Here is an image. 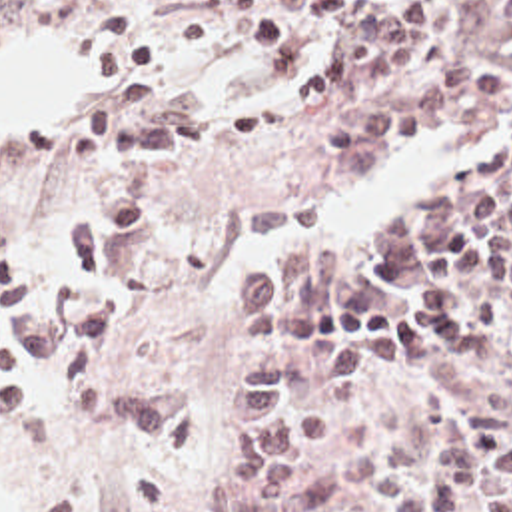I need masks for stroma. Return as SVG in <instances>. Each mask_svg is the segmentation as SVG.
Listing matches in <instances>:
<instances>
[{"instance_id":"1","label":"stroma","mask_w":512,"mask_h":512,"mask_svg":"<svg viewBox=\"0 0 512 512\" xmlns=\"http://www.w3.org/2000/svg\"><path fill=\"white\" fill-rule=\"evenodd\" d=\"M511 1L457 0L401 73L345 87L323 109H293L285 87L337 49L339 35L323 21L309 57L291 73L271 77L283 99L277 131L250 145L164 151L158 157V203L144 235L130 249L110 251L100 279L74 283L70 303L104 291L126 299L130 319L96 367L116 385L184 389L196 403V425L172 438H140L118 419H84L62 399L50 371H16L12 377L42 403L48 428L12 421L0 409V512H138L134 476L144 472L170 484L178 512H212L218 480L242 456L234 425L240 381L265 363L295 365L315 355L295 347L238 349L236 295H216L218 265L238 239L254 231L319 217L335 191L365 179L385 153L327 151L319 143V127L457 69L489 71L512 85V27L503 15ZM76 3L0 0V41L24 27L44 25L68 45ZM198 5L200 0H130L134 21L152 43L148 67L136 73L150 101L134 127L164 109L216 121L265 103L232 99L212 105L166 71L162 51L198 49L218 37L238 65L267 75L262 55L238 39L226 19L206 29L202 41L186 43L182 31ZM116 83L90 85L60 121L0 123V251H18L32 281L46 279L66 225L124 181L126 159L74 163L66 151L68 127L84 105ZM499 133H509L511 141L512 117L463 123L457 137L475 143ZM289 399L327 415L337 438L307 462L301 494L285 512H387L343 482V448L379 440L427 468L433 428L451 407H467L475 415L487 448L512 440V369L497 379H461L411 349L403 373L377 389L343 401L317 391ZM238 512L254 510L240 506Z\"/></svg>"}]
</instances>
